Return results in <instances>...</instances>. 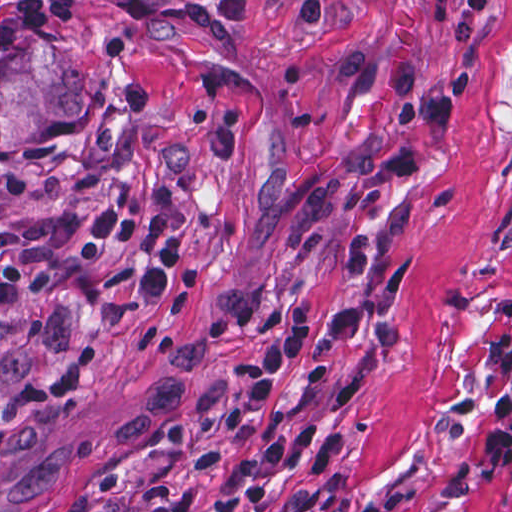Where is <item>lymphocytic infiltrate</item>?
I'll return each instance as SVG.
<instances>
[{
    "mask_svg": "<svg viewBox=\"0 0 512 512\" xmlns=\"http://www.w3.org/2000/svg\"><path fill=\"white\" fill-rule=\"evenodd\" d=\"M332 0H300L295 21L320 31ZM72 0H14L0 14V54L16 52L38 29L66 23ZM341 87L351 96L385 93L397 101L401 130L384 162L387 177H408L430 160L454 115L451 94H430L416 59L381 60L356 48L337 55ZM74 218L61 213L12 231H0V305L37 291L54 272L51 252L63 249L90 260L107 242L132 251L140 263L139 292L149 307H163L181 243L172 220L147 211L118 193L100 200L91 231L72 232ZM321 309L307 300L291 306L269 325L257 343L249 371L230 391L222 410L179 427L173 443L206 440L166 468L150 473L118 461L99 485L76 498L64 512H195L208 480L247 458L262 438L266 420L280 403L307 339L318 329ZM86 359L65 353L0 406V442L48 399L75 390L87 377ZM487 470L512 468V383L495 398L492 419L481 436ZM272 512H360L345 496L313 490Z\"/></svg>",
    "mask_w": 512,
    "mask_h": 512,
    "instance_id": "lymphocytic-infiltrate-1",
    "label": "lymphocytic infiltrate"
}]
</instances>
